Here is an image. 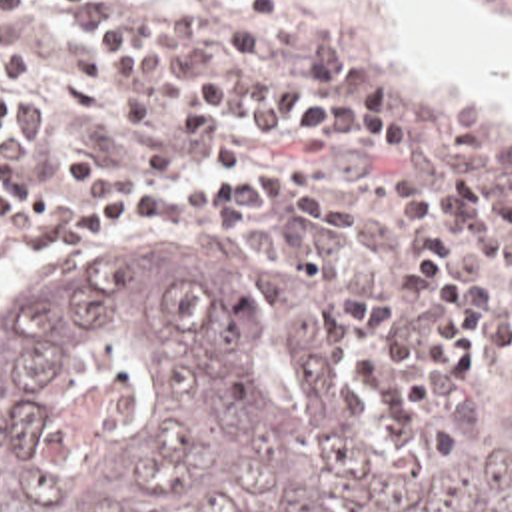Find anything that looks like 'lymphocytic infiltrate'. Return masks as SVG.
Listing matches in <instances>:
<instances>
[{
  "label": "lymphocytic infiltrate",
  "instance_id": "obj_1",
  "mask_svg": "<svg viewBox=\"0 0 512 512\" xmlns=\"http://www.w3.org/2000/svg\"><path fill=\"white\" fill-rule=\"evenodd\" d=\"M68 33L72 109L76 123L108 109L128 156L118 168L90 148L66 150V186L56 188L12 146L22 111L16 77L38 61L34 35L0 45V236L32 250L112 236L126 226L184 224L206 214H238L256 204V172L230 170L192 186H162L150 176L172 174L178 158L162 144L156 121L176 105V79L188 77L168 137L202 154L222 115L268 121H312L340 137H358L388 154L416 152V119L402 103L396 79L348 75L326 57L298 55L302 79H234L198 71L212 43L196 29L184 0H48ZM290 0H220L218 43L232 57H256L282 27ZM454 202L434 198L418 180L396 184L404 218L416 228L400 254L402 266L434 296V320L422 334L402 332L396 298L384 292L340 294L348 322L374 340L366 368L380 386L388 418H410L438 398L444 380H464L482 366V306L460 286H486L492 264L512 286V178H496L468 162L446 174ZM468 226H496L462 234Z\"/></svg>",
  "mask_w": 512,
  "mask_h": 512
}]
</instances>
